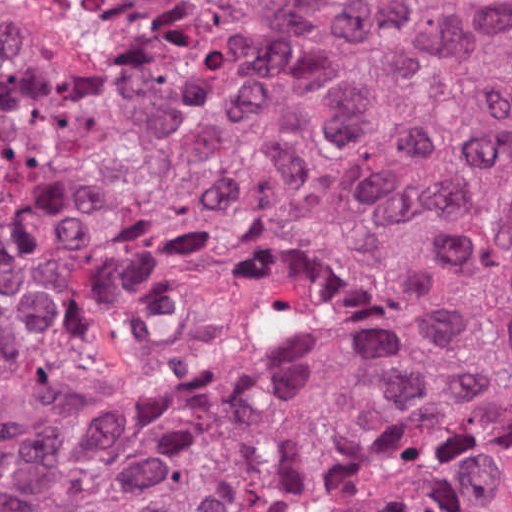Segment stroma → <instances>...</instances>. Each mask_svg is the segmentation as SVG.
I'll return each mask as SVG.
<instances>
[{
    "instance_id": "obj_1",
    "label": "stroma",
    "mask_w": 512,
    "mask_h": 512,
    "mask_svg": "<svg viewBox=\"0 0 512 512\" xmlns=\"http://www.w3.org/2000/svg\"><path fill=\"white\" fill-rule=\"evenodd\" d=\"M127 1L512 0H0V32L79 82L126 86L155 70L141 20Z\"/></svg>"
}]
</instances>
